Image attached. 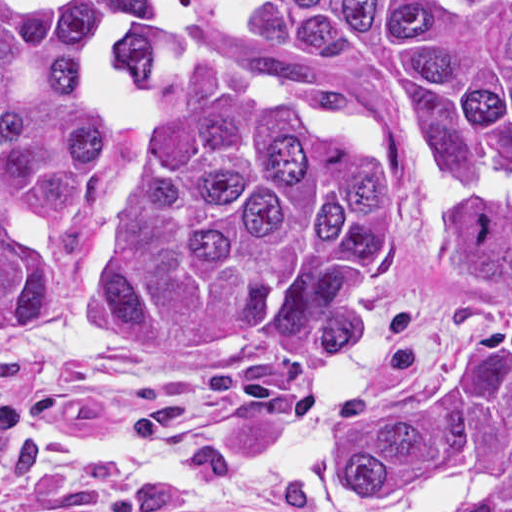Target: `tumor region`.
Masks as SVG:
<instances>
[{
    "label": "tumor region",
    "mask_w": 512,
    "mask_h": 512,
    "mask_svg": "<svg viewBox=\"0 0 512 512\" xmlns=\"http://www.w3.org/2000/svg\"><path fill=\"white\" fill-rule=\"evenodd\" d=\"M410 174L488 178L433 225L468 321L367 391L332 464L382 489L455 470L466 512H512V0H0V342L58 310L128 360L356 361ZM13 434L0 409V469Z\"/></svg>",
    "instance_id": "1"
}]
</instances>
